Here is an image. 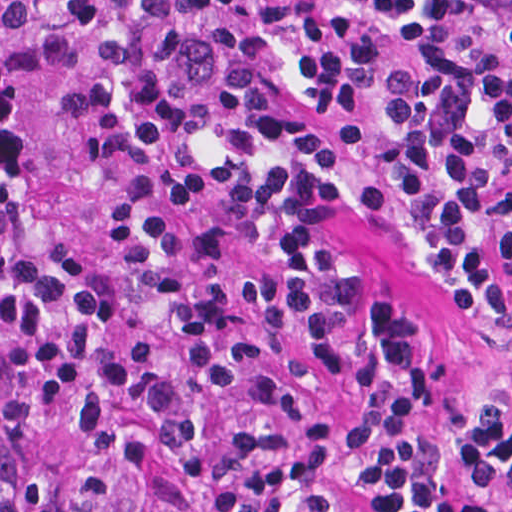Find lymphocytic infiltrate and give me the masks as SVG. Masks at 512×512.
Listing matches in <instances>:
<instances>
[{
  "label": "lymphocytic infiltrate",
  "instance_id": "obj_1",
  "mask_svg": "<svg viewBox=\"0 0 512 512\" xmlns=\"http://www.w3.org/2000/svg\"><path fill=\"white\" fill-rule=\"evenodd\" d=\"M163 161L210 290L207 425L183 512H481L436 355L379 302L355 414L300 425L265 354L331 360L370 210L495 363L477 450L512 486V0H71L53 9Z\"/></svg>",
  "mask_w": 512,
  "mask_h": 512
}]
</instances>
